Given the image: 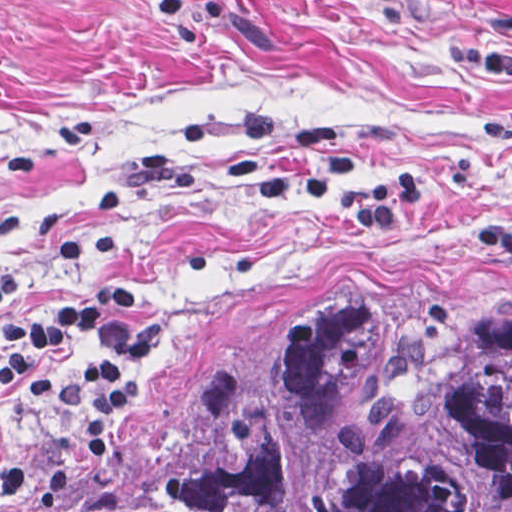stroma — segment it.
<instances>
[{
    "label": "stroma",
    "instance_id": "obj_1",
    "mask_svg": "<svg viewBox=\"0 0 512 512\" xmlns=\"http://www.w3.org/2000/svg\"><path fill=\"white\" fill-rule=\"evenodd\" d=\"M387 141L434 188L398 240L327 204L264 201L305 166L297 129ZM0 327L67 295L59 253L115 228L104 283L157 337L108 413L87 346L58 352L107 444L187 413L365 320L426 304L512 309V0H0ZM82 452L62 400L0 387V512H36Z\"/></svg>",
    "mask_w": 512,
    "mask_h": 512
}]
</instances>
